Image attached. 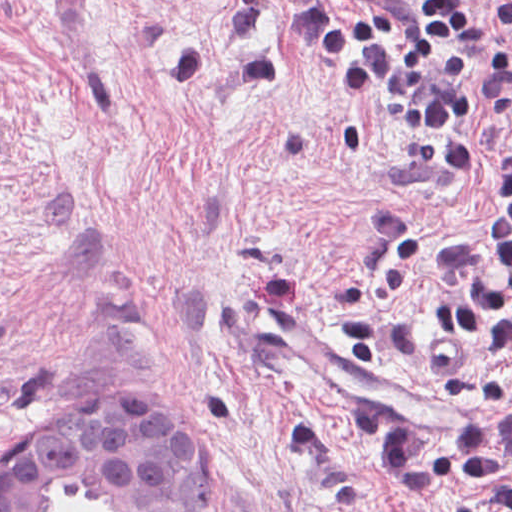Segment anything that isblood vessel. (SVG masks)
<instances>
[{"instance_id": "obj_1", "label": "blood vessel", "mask_w": 512, "mask_h": 512, "mask_svg": "<svg viewBox=\"0 0 512 512\" xmlns=\"http://www.w3.org/2000/svg\"><path fill=\"white\" fill-rule=\"evenodd\" d=\"M313 378L334 400L379 414L416 435H449L464 426V407L432 386L379 364H353L346 350L319 335Z\"/></svg>"}]
</instances>
